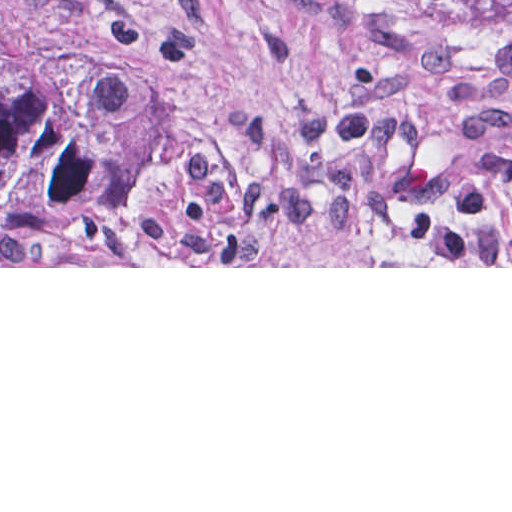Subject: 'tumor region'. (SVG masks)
Returning <instances> with one entry per match:
<instances>
[{"instance_id": "obj_1", "label": "tumor region", "mask_w": 512, "mask_h": 512, "mask_svg": "<svg viewBox=\"0 0 512 512\" xmlns=\"http://www.w3.org/2000/svg\"><path fill=\"white\" fill-rule=\"evenodd\" d=\"M446 15L474 27L512 28V0H425Z\"/></svg>"}]
</instances>
